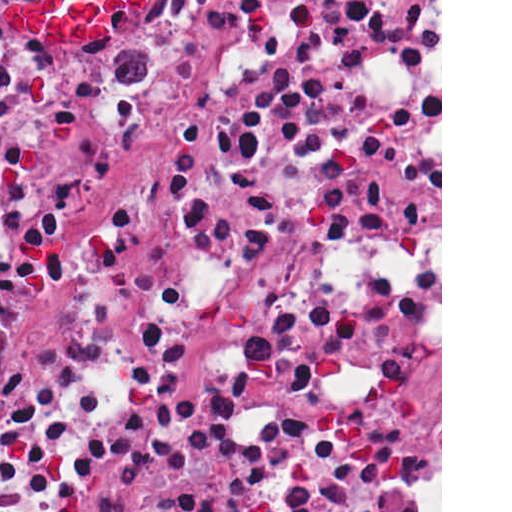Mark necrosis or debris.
<instances>
[{
    "label": "necrosis or debris",
    "mask_w": 512,
    "mask_h": 512,
    "mask_svg": "<svg viewBox=\"0 0 512 512\" xmlns=\"http://www.w3.org/2000/svg\"><path fill=\"white\" fill-rule=\"evenodd\" d=\"M0 512H40L1 422Z\"/></svg>",
    "instance_id": "4bbe7bcc"
}]
</instances>
